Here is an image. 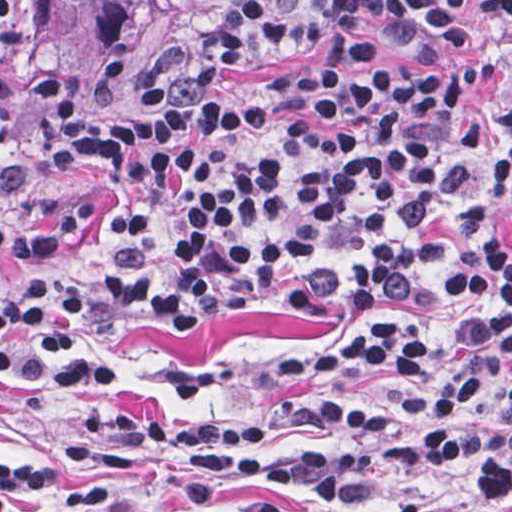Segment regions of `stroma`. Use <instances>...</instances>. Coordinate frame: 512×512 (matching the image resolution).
<instances>
[{"mask_svg": "<svg viewBox=\"0 0 512 512\" xmlns=\"http://www.w3.org/2000/svg\"><path fill=\"white\" fill-rule=\"evenodd\" d=\"M100 0H74L45 9L34 34L37 64L74 83L94 70L84 16ZM246 0H170L139 15L115 87L116 113L135 116V82L151 58L177 45L202 18L239 10ZM458 36H435L395 47L391 65L420 67L468 51H489L498 65L472 93L470 112L488 150H497L499 128L512 105V10L486 0H459ZM319 44L295 45L252 65L229 66V91H254L295 60L318 59ZM108 183L77 161H49L36 145V108L24 66L6 61L0 92V227L26 232L104 193ZM128 197L101 198V219L91 244L43 269L16 272L0 262V300L24 298L31 282L48 275L61 287L84 283L85 317L77 333L89 352L122 370L119 383L79 392H46L0 380V460L33 456L83 481L69 448V431L89 403L183 413L207 422L261 419L276 424L272 440L282 453L330 449L334 444L292 419L278 368L299 364L329 333L326 312L308 295L266 292L222 300L205 308L162 316L121 317L94 300L92 286L125 217ZM512 395V357L482 402L486 419L501 413ZM481 463L448 459L404 463L382 450L352 487L325 500H290L285 512H420L432 498H453L474 485ZM151 486L131 498L100 506L50 512H153L162 496ZM211 512H241L230 493L213 489ZM493 512H512V504Z\"/></svg>", "mask_w": 512, "mask_h": 512, "instance_id": "stroma-1", "label": "stroma"}]
</instances>
